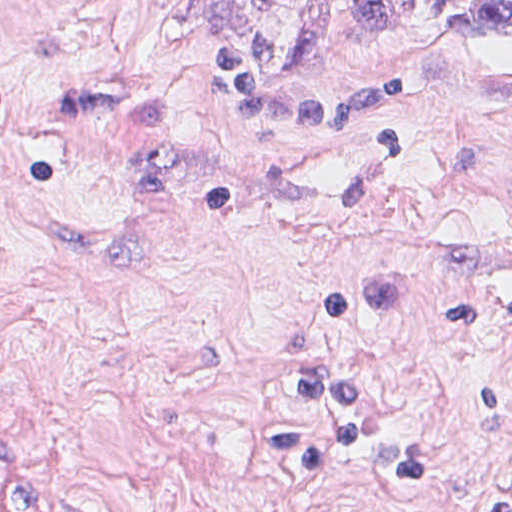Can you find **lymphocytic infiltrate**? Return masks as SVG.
<instances>
[{
  "label": "lymphocytic infiltrate",
  "instance_id": "f902f5d3",
  "mask_svg": "<svg viewBox=\"0 0 512 512\" xmlns=\"http://www.w3.org/2000/svg\"><path fill=\"white\" fill-rule=\"evenodd\" d=\"M19 125V106L10 89L0 80V146L13 139Z\"/></svg>",
  "mask_w": 512,
  "mask_h": 512
}]
</instances>
